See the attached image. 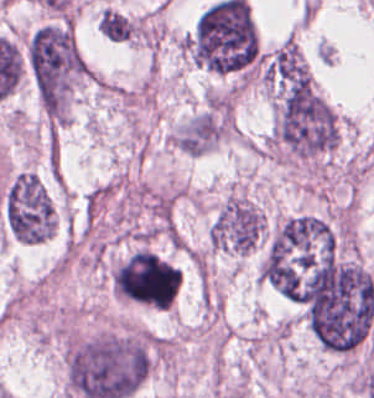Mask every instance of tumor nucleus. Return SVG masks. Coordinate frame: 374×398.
I'll use <instances>...</instances> for the list:
<instances>
[{"label": "tumor nucleus", "instance_id": "tumor-nucleus-1", "mask_svg": "<svg viewBox=\"0 0 374 398\" xmlns=\"http://www.w3.org/2000/svg\"><path fill=\"white\" fill-rule=\"evenodd\" d=\"M0 206L3 226L15 239L39 243L56 229V206L46 185L31 168L10 176L3 187Z\"/></svg>", "mask_w": 374, "mask_h": 398}]
</instances>
